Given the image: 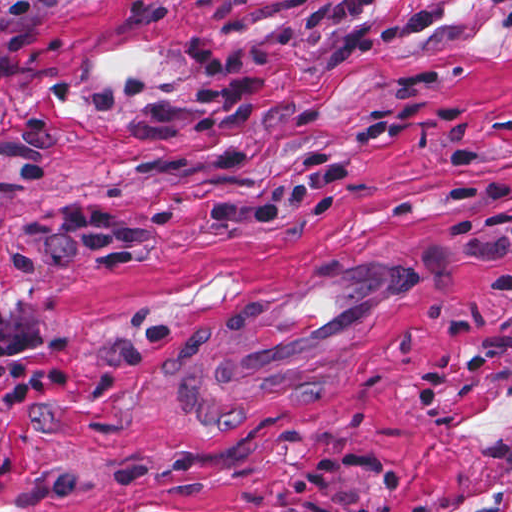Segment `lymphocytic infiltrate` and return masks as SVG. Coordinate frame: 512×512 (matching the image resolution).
Wrapping results in <instances>:
<instances>
[{
	"instance_id": "f902f5d3",
	"label": "lymphocytic infiltrate",
	"mask_w": 512,
	"mask_h": 512,
	"mask_svg": "<svg viewBox=\"0 0 512 512\" xmlns=\"http://www.w3.org/2000/svg\"><path fill=\"white\" fill-rule=\"evenodd\" d=\"M387 0H310L302 10L300 29L309 38H337L326 67L389 47L436 21L433 8L407 12L385 29L369 20L373 4ZM190 82L184 98L159 99L149 81L130 76L121 84L92 89L88 112L100 115L138 104L132 140L163 144L198 131H210L214 160L222 169L243 171L248 164V126L270 105L274 78L267 74L274 56L266 44L222 48L196 41L187 51ZM458 120L462 111L451 100L382 102L355 119L341 154L318 150L307 156L295 176L261 197L236 198L208 206L205 222L221 230H268L297 211L330 214L335 196L352 184L365 150L402 135L423 116ZM35 240L20 244L11 258L12 271L58 266L71 253L114 271L136 261L156 239L154 228L131 211L75 204L65 211L43 213L29 224ZM451 241L474 259L495 255L512 261V225L492 226L474 211L453 218ZM479 291L488 299H512V263L482 279ZM69 370L63 345L30 322L0 309V431L10 430L44 410L67 401Z\"/></svg>"
}]
</instances>
